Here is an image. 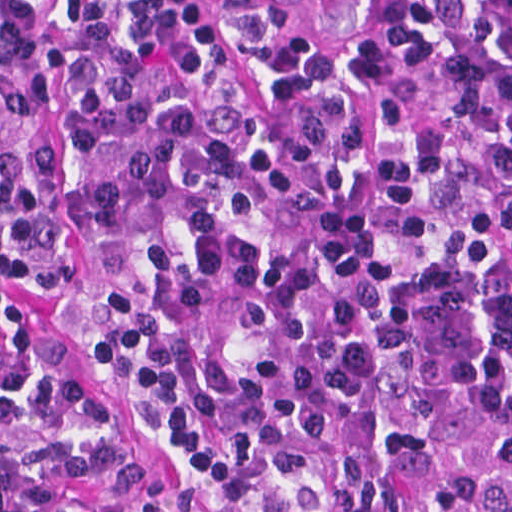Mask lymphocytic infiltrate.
<instances>
[{"label": "lymphocytic infiltrate", "instance_id": "f902f5d3", "mask_svg": "<svg viewBox=\"0 0 512 512\" xmlns=\"http://www.w3.org/2000/svg\"><path fill=\"white\" fill-rule=\"evenodd\" d=\"M0 512H512V0H0Z\"/></svg>", "mask_w": 512, "mask_h": 512}]
</instances>
